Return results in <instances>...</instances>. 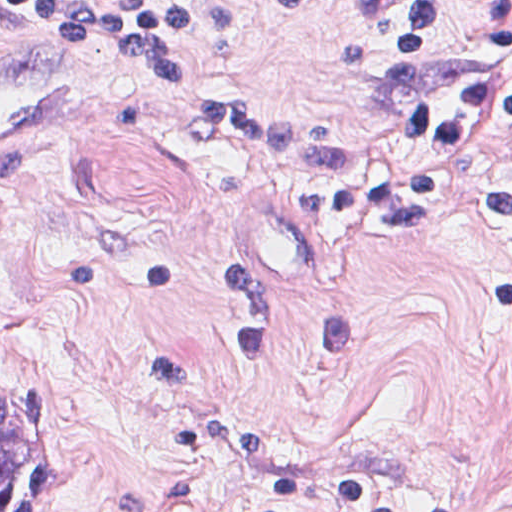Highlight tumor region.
I'll return each mask as SVG.
<instances>
[{
  "label": "tumor region",
  "mask_w": 512,
  "mask_h": 512,
  "mask_svg": "<svg viewBox=\"0 0 512 512\" xmlns=\"http://www.w3.org/2000/svg\"><path fill=\"white\" fill-rule=\"evenodd\" d=\"M0 512H58V447L48 397L21 364L0 358Z\"/></svg>",
  "instance_id": "obj_1"
}]
</instances>
